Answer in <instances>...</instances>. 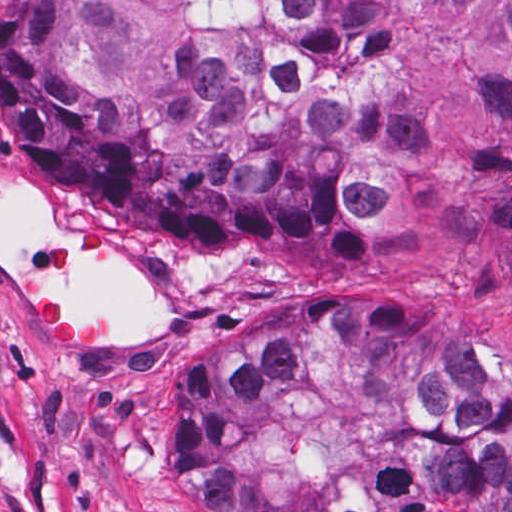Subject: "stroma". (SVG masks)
Masks as SVG:
<instances>
[{"label": "stroma", "instance_id": "1", "mask_svg": "<svg viewBox=\"0 0 512 512\" xmlns=\"http://www.w3.org/2000/svg\"><path fill=\"white\" fill-rule=\"evenodd\" d=\"M496 11L497 0H460L451 19L411 3L369 101L427 135L430 201L370 222L333 255L288 253L261 278H235L223 264L179 262L37 175L1 121L0 0V512H183L187 421L205 378L332 306L400 310L435 343L459 344L512 381V242L459 220L478 161L467 106L449 93L450 70L488 43ZM1 170L52 204L61 229L31 243V272L1 266ZM77 258L129 259L163 325L119 332L105 307H72L51 279ZM36 297L98 329L95 347L51 351L30 315Z\"/></svg>", "mask_w": 512, "mask_h": 512}]
</instances>
